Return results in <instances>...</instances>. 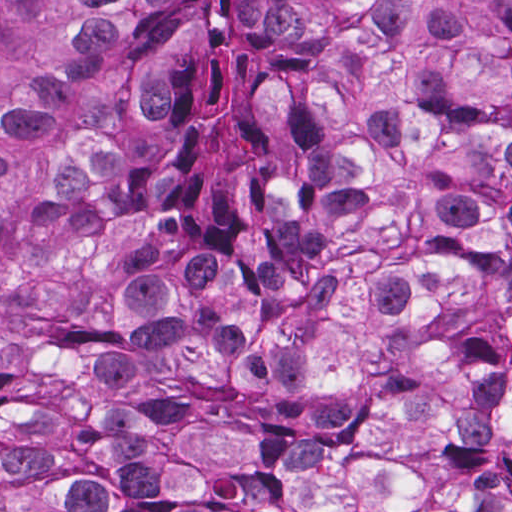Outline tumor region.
I'll use <instances>...</instances> for the list:
<instances>
[{
	"label": "tumor region",
	"instance_id": "1",
	"mask_svg": "<svg viewBox=\"0 0 512 512\" xmlns=\"http://www.w3.org/2000/svg\"><path fill=\"white\" fill-rule=\"evenodd\" d=\"M1 512H512V1H1Z\"/></svg>",
	"mask_w": 512,
	"mask_h": 512
}]
</instances>
